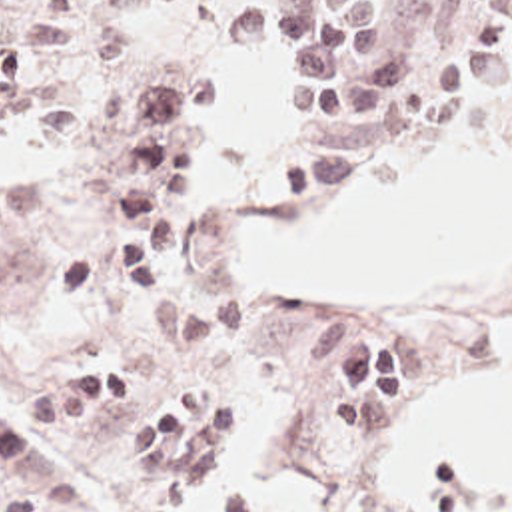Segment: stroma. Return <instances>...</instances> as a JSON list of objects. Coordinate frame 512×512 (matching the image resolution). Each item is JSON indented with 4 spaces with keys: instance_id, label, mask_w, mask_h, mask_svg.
Segmentation results:
<instances>
[{
    "instance_id": "stroma-1",
    "label": "stroma",
    "mask_w": 512,
    "mask_h": 512,
    "mask_svg": "<svg viewBox=\"0 0 512 512\" xmlns=\"http://www.w3.org/2000/svg\"><path fill=\"white\" fill-rule=\"evenodd\" d=\"M254 2L280 0H155L117 20L67 10L79 41L53 71L77 111L97 115L133 85L179 65L202 69L216 95L175 285L161 303L59 305L51 289L59 273L97 249L121 211L123 155L65 127L13 131L0 123V501L43 503L47 512H181L151 511L137 499L133 455L113 447L125 417L35 427L27 407L55 385L119 363L145 365L153 399L234 393L222 363L240 349L284 401L288 457L302 471V512H512V487L478 477L468 461H442L418 495H400L396 479V437L418 411L498 375L486 335L512 323V285H294L226 251L236 225L322 209L376 163L404 161L436 117H468L486 143L512 151V83L472 99L438 93L450 61L488 49L482 28L512 16V0H394L396 37L434 65V91L410 133L330 185L270 181L278 157L344 127L308 131L288 121L296 79L276 49L238 53L222 45V24ZM360 113L356 105L354 117ZM344 301L388 317L408 343V407L374 435H342L348 431L328 385L304 379L296 359L304 325Z\"/></svg>"
}]
</instances>
